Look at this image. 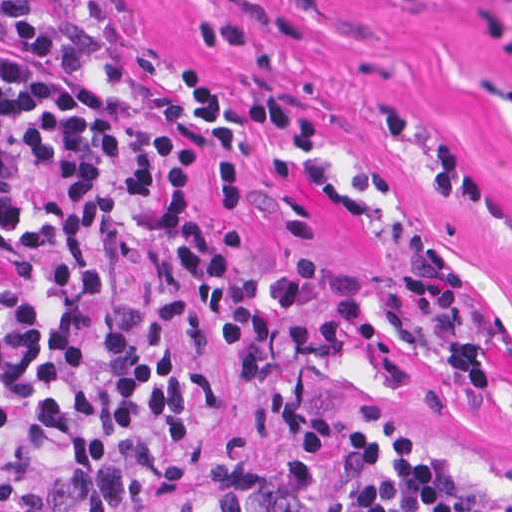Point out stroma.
Wrapping results in <instances>:
<instances>
[{
  "mask_svg": "<svg viewBox=\"0 0 512 512\" xmlns=\"http://www.w3.org/2000/svg\"><path fill=\"white\" fill-rule=\"evenodd\" d=\"M15 22L68 49L73 69L125 89L150 126L205 145L202 176L162 232L113 236V300L146 312L224 403L214 438L152 466L153 503L171 507L252 454L299 468L311 512H349L363 489L420 453L512 491V0H0V61L21 65L32 62L3 30ZM181 65L207 67L237 101L284 90L320 120L308 142L263 132L243 140L236 211L206 191L208 140L189 114ZM183 224L208 239L239 224L238 265L264 281L293 255H315L323 276L360 281L381 326L423 346H432L429 326L400 283L415 250L437 246L459 283L458 319L483 351L487 390L449 388L407 363L412 381L400 387L355 344L332 362L301 363L296 387L319 415L376 412L421 450L340 466L296 457L213 339L234 321L327 312L186 303L169 260Z\"/></svg>",
  "mask_w": 512,
  "mask_h": 512,
  "instance_id": "obj_1",
  "label": "stroma"
}]
</instances>
